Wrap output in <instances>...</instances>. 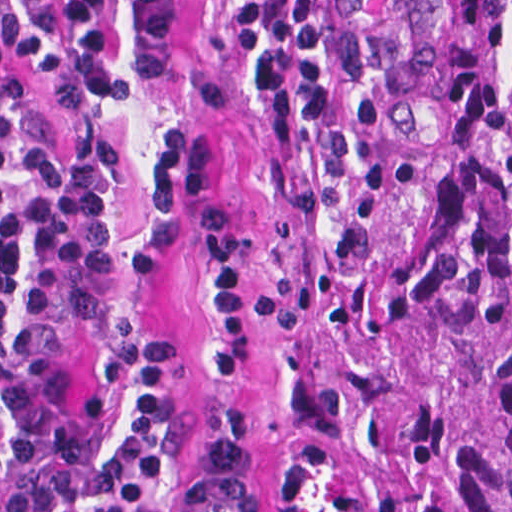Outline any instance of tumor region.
Masks as SVG:
<instances>
[{
	"mask_svg": "<svg viewBox=\"0 0 512 512\" xmlns=\"http://www.w3.org/2000/svg\"><path fill=\"white\" fill-rule=\"evenodd\" d=\"M389 174L332 512H512V0H341Z\"/></svg>",
	"mask_w": 512,
	"mask_h": 512,
	"instance_id": "tumor-region-1",
	"label": "tumor region"
}]
</instances>
